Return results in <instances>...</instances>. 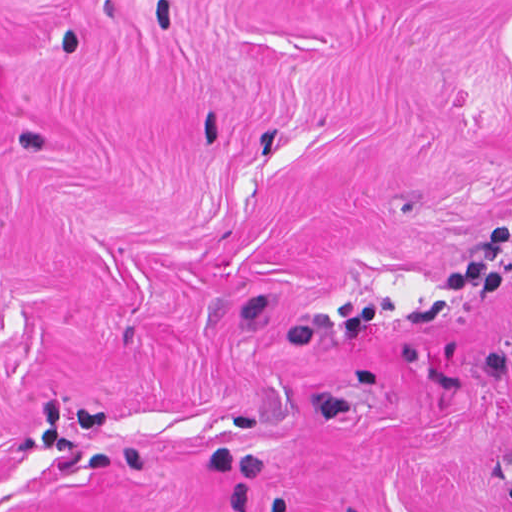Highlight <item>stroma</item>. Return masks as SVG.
<instances>
[{
    "label": "stroma",
    "mask_w": 512,
    "mask_h": 512,
    "mask_svg": "<svg viewBox=\"0 0 512 512\" xmlns=\"http://www.w3.org/2000/svg\"><path fill=\"white\" fill-rule=\"evenodd\" d=\"M0 512H512V0H0Z\"/></svg>",
    "instance_id": "1"
}]
</instances>
